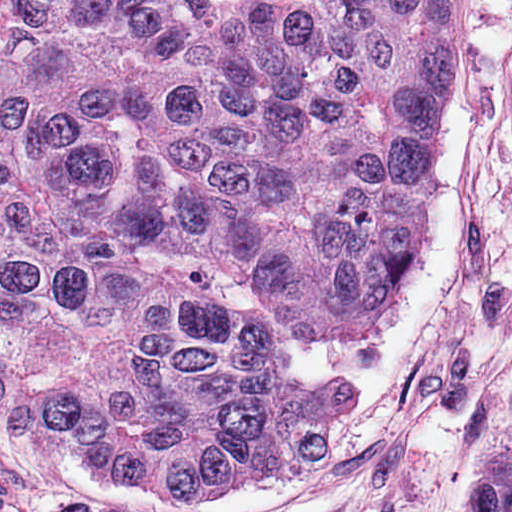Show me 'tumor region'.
<instances>
[{"label":"tumor region","mask_w":512,"mask_h":512,"mask_svg":"<svg viewBox=\"0 0 512 512\" xmlns=\"http://www.w3.org/2000/svg\"><path fill=\"white\" fill-rule=\"evenodd\" d=\"M449 0H0V374L83 464L215 506L365 392L277 343L393 312ZM464 512H512V430Z\"/></svg>","instance_id":"obj_1"}]
</instances>
